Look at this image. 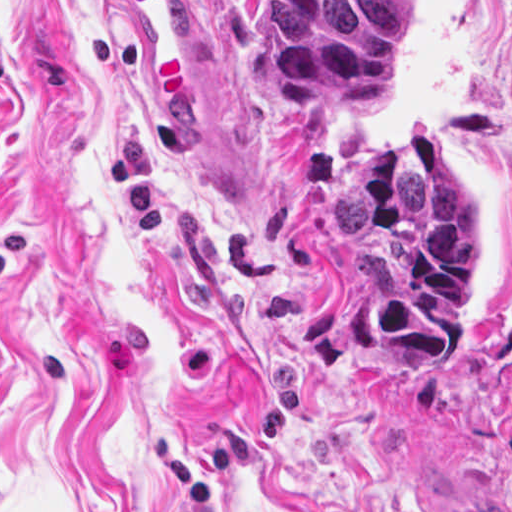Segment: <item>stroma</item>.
Here are the masks:
<instances>
[{"instance_id": "obj_1", "label": "stroma", "mask_w": 512, "mask_h": 512, "mask_svg": "<svg viewBox=\"0 0 512 512\" xmlns=\"http://www.w3.org/2000/svg\"><path fill=\"white\" fill-rule=\"evenodd\" d=\"M206 117L142 119L117 0H0V512H512V0H414L376 115L271 98L261 0H193ZM425 127L472 337L353 343L331 179Z\"/></svg>"}]
</instances>
